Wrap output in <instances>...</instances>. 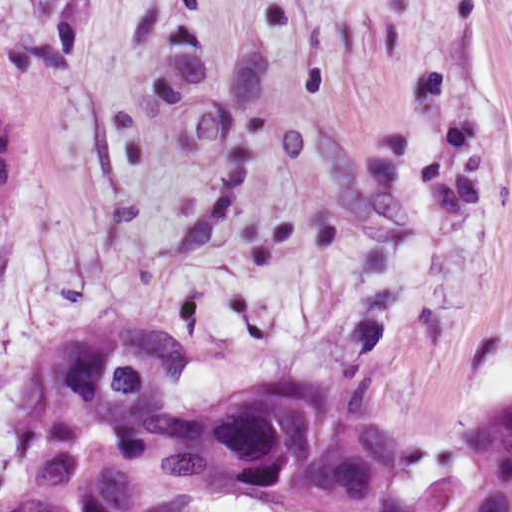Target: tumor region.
I'll return each mask as SVG.
<instances>
[{"label":"tumor region","instance_id":"1","mask_svg":"<svg viewBox=\"0 0 512 512\" xmlns=\"http://www.w3.org/2000/svg\"><path fill=\"white\" fill-rule=\"evenodd\" d=\"M25 122L0 104V219L18 197ZM180 350L114 327L40 355L0 453V512H512V389L469 417L472 473L429 500L391 470L373 410L339 378L291 372L207 413Z\"/></svg>","mask_w":512,"mask_h":512}]
</instances>
